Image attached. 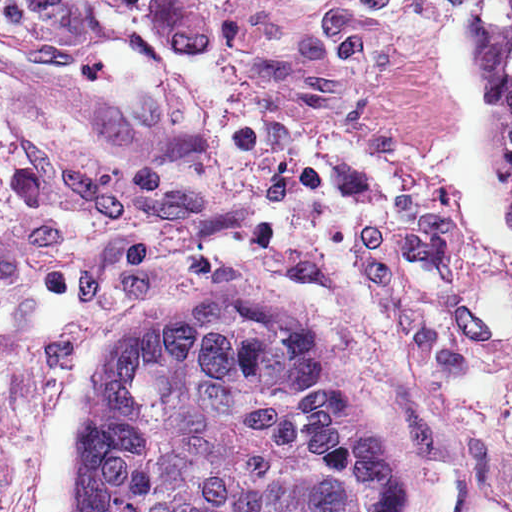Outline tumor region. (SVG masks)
I'll return each instance as SVG.
<instances>
[{"label":"tumor region","mask_w":512,"mask_h":512,"mask_svg":"<svg viewBox=\"0 0 512 512\" xmlns=\"http://www.w3.org/2000/svg\"><path fill=\"white\" fill-rule=\"evenodd\" d=\"M72 512H314L217 293L125 325Z\"/></svg>","instance_id":"tumor-region-1"}]
</instances>
